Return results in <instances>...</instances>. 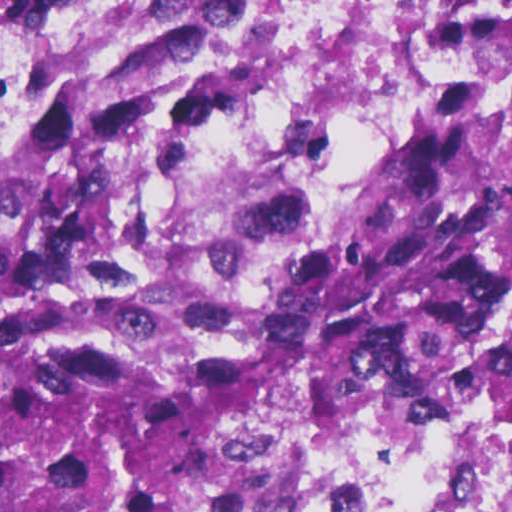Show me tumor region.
Masks as SVG:
<instances>
[{"label":"tumor region","mask_w":512,"mask_h":512,"mask_svg":"<svg viewBox=\"0 0 512 512\" xmlns=\"http://www.w3.org/2000/svg\"><path fill=\"white\" fill-rule=\"evenodd\" d=\"M263 0H156L0 135V512H242L512 289V104L449 103L361 209L235 245L194 161Z\"/></svg>","instance_id":"tumor-region-1"}]
</instances>
